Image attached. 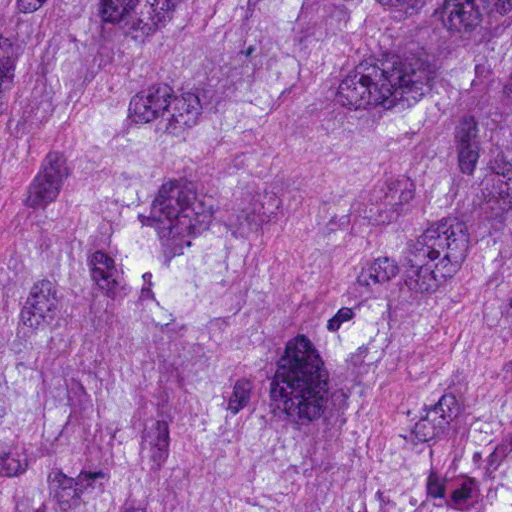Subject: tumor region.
Wrapping results in <instances>:
<instances>
[{
  "instance_id": "e687c5a6",
  "label": "tumor region",
  "mask_w": 512,
  "mask_h": 512,
  "mask_svg": "<svg viewBox=\"0 0 512 512\" xmlns=\"http://www.w3.org/2000/svg\"><path fill=\"white\" fill-rule=\"evenodd\" d=\"M0 512H512V0H0Z\"/></svg>"
}]
</instances>
